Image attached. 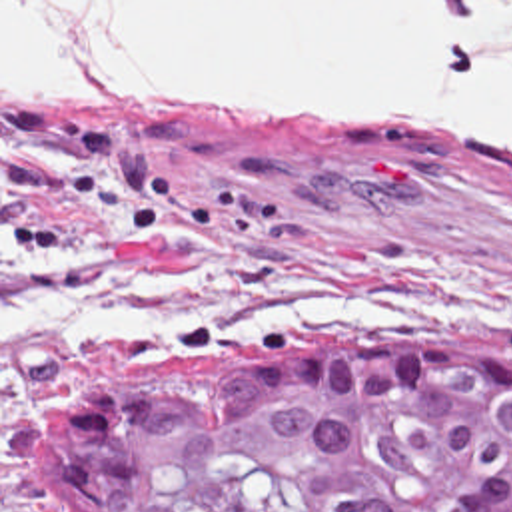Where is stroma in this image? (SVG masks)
Masks as SVG:
<instances>
[{
  "mask_svg": "<svg viewBox=\"0 0 512 512\" xmlns=\"http://www.w3.org/2000/svg\"><path fill=\"white\" fill-rule=\"evenodd\" d=\"M0 512L36 429L142 363L413 337L512 371V140L339 104H2Z\"/></svg>",
  "mask_w": 512,
  "mask_h": 512,
  "instance_id": "obj_1",
  "label": "stroma"
}]
</instances>
